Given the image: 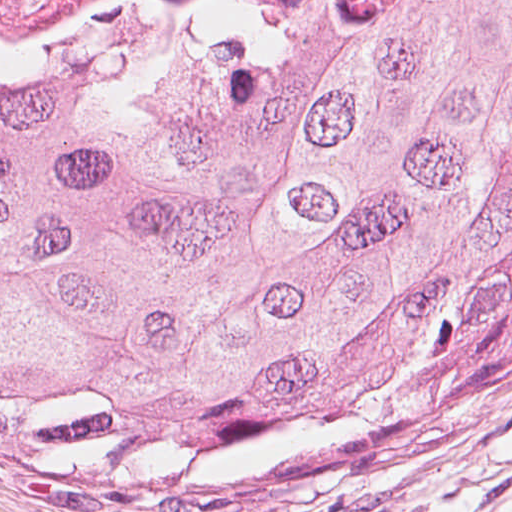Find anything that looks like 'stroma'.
<instances>
[{"instance_id":"obj_1","label":"stroma","mask_w":512,"mask_h":512,"mask_svg":"<svg viewBox=\"0 0 512 512\" xmlns=\"http://www.w3.org/2000/svg\"><path fill=\"white\" fill-rule=\"evenodd\" d=\"M236 7L70 29L36 40L93 37L197 17L232 27ZM135 480L100 432L0 410V512H129Z\"/></svg>"}]
</instances>
